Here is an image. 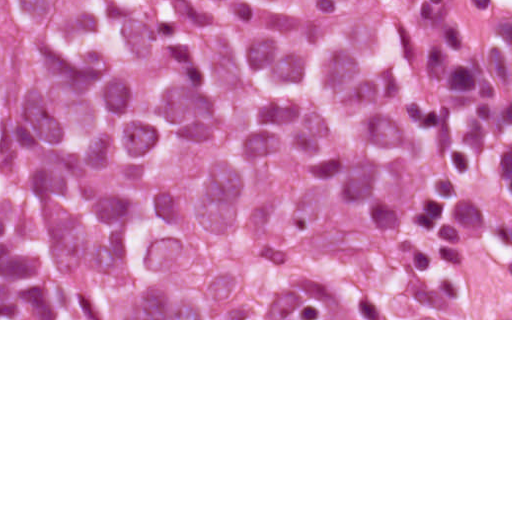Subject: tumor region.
<instances>
[{"mask_svg":"<svg viewBox=\"0 0 512 512\" xmlns=\"http://www.w3.org/2000/svg\"><path fill=\"white\" fill-rule=\"evenodd\" d=\"M0 318H512V38L455 0H0Z\"/></svg>","mask_w":512,"mask_h":512,"instance_id":"tumor-region-1","label":"tumor region"}]
</instances>
